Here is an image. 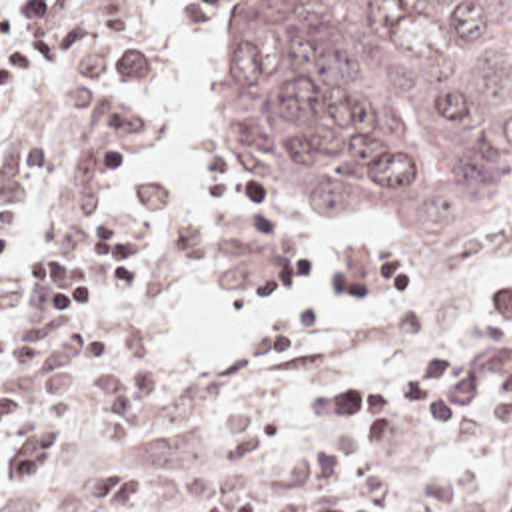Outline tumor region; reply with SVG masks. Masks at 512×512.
Here are the masks:
<instances>
[{
	"label": "tumor region",
	"instance_id": "e687c5a6",
	"mask_svg": "<svg viewBox=\"0 0 512 512\" xmlns=\"http://www.w3.org/2000/svg\"><path fill=\"white\" fill-rule=\"evenodd\" d=\"M228 184L387 218L425 274L489 254L512 202V2H208Z\"/></svg>",
	"mask_w": 512,
	"mask_h": 512
}]
</instances>
